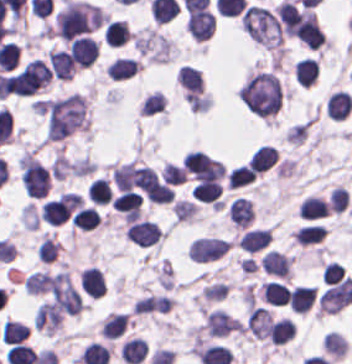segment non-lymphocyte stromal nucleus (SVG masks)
Instances as JSON below:
<instances>
[{
	"instance_id": "4",
	"label": "non-lymphocyte stromal nucleus",
	"mask_w": 352,
	"mask_h": 364,
	"mask_svg": "<svg viewBox=\"0 0 352 364\" xmlns=\"http://www.w3.org/2000/svg\"><path fill=\"white\" fill-rule=\"evenodd\" d=\"M238 327V319L222 309L207 311L205 315V331L212 336L227 335Z\"/></svg>"
},
{
	"instance_id": "3",
	"label": "non-lymphocyte stromal nucleus",
	"mask_w": 352,
	"mask_h": 364,
	"mask_svg": "<svg viewBox=\"0 0 352 364\" xmlns=\"http://www.w3.org/2000/svg\"><path fill=\"white\" fill-rule=\"evenodd\" d=\"M40 286L62 316L80 311L82 295L67 269L42 272Z\"/></svg>"
},
{
	"instance_id": "5",
	"label": "non-lymphocyte stromal nucleus",
	"mask_w": 352,
	"mask_h": 364,
	"mask_svg": "<svg viewBox=\"0 0 352 364\" xmlns=\"http://www.w3.org/2000/svg\"><path fill=\"white\" fill-rule=\"evenodd\" d=\"M227 216L233 227H247L253 216L249 201L238 196L234 197L229 202Z\"/></svg>"
},
{
	"instance_id": "1",
	"label": "non-lymphocyte stromal nucleus",
	"mask_w": 352,
	"mask_h": 364,
	"mask_svg": "<svg viewBox=\"0 0 352 364\" xmlns=\"http://www.w3.org/2000/svg\"><path fill=\"white\" fill-rule=\"evenodd\" d=\"M45 136L62 139L87 125L84 98L78 92L46 98L41 104Z\"/></svg>"
},
{
	"instance_id": "2",
	"label": "non-lymphocyte stromal nucleus",
	"mask_w": 352,
	"mask_h": 364,
	"mask_svg": "<svg viewBox=\"0 0 352 364\" xmlns=\"http://www.w3.org/2000/svg\"><path fill=\"white\" fill-rule=\"evenodd\" d=\"M103 11L85 0H66L55 14L53 32L73 39L85 35L105 21Z\"/></svg>"
}]
</instances>
